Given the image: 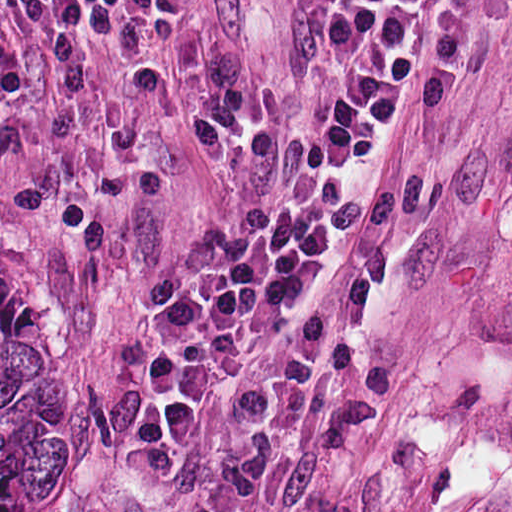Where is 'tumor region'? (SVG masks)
Segmentation results:
<instances>
[{"label":"tumor region","mask_w":512,"mask_h":512,"mask_svg":"<svg viewBox=\"0 0 512 512\" xmlns=\"http://www.w3.org/2000/svg\"><path fill=\"white\" fill-rule=\"evenodd\" d=\"M0 512H63V355L1 241Z\"/></svg>","instance_id":"tumor-region-1"}]
</instances>
